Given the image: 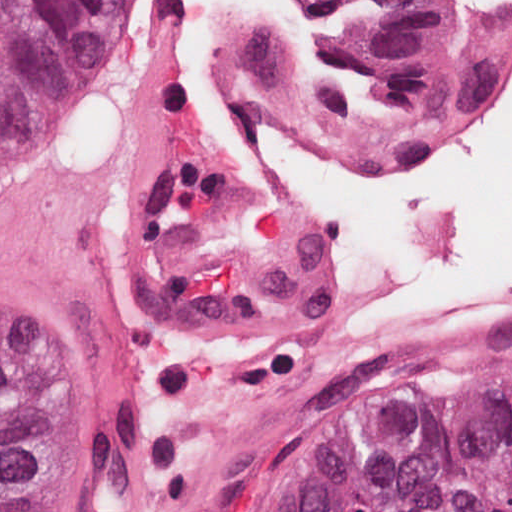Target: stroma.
<instances>
[{
  "instance_id": "1",
  "label": "stroma",
  "mask_w": 512,
  "mask_h": 512,
  "mask_svg": "<svg viewBox=\"0 0 512 512\" xmlns=\"http://www.w3.org/2000/svg\"><path fill=\"white\" fill-rule=\"evenodd\" d=\"M437 2L455 17L498 19L481 0ZM148 4L149 0H135L117 47L76 119L32 166L0 187V222H34L39 196L106 131L129 83ZM511 79L512 46L504 77L489 101L467 117L426 129L487 125L497 119ZM0 342L15 345L46 385L50 403L46 512H113L118 454L108 428L67 377L33 344L5 331H0ZM453 376L512 378V323L407 344L322 378L299 397L261 480L253 512H268L290 481L344 438L385 414L431 400L435 380Z\"/></svg>"
}]
</instances>
